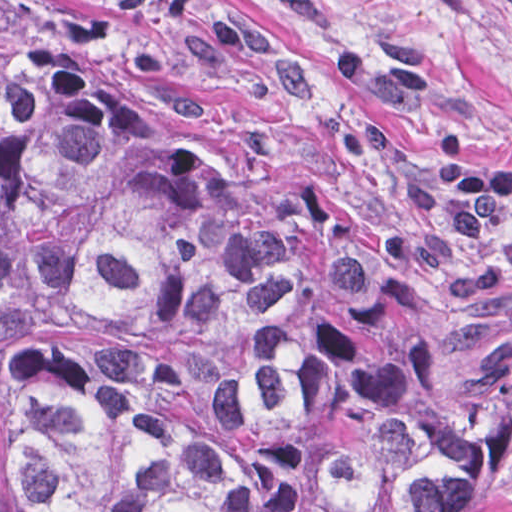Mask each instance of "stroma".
Returning a JSON list of instances; mask_svg holds the SVG:
<instances>
[{
    "label": "stroma",
    "mask_w": 512,
    "mask_h": 512,
    "mask_svg": "<svg viewBox=\"0 0 512 512\" xmlns=\"http://www.w3.org/2000/svg\"><path fill=\"white\" fill-rule=\"evenodd\" d=\"M247 209L347 221L341 137L512 179V0H0ZM450 512H512V450Z\"/></svg>",
    "instance_id": "stroma-1"
}]
</instances>
